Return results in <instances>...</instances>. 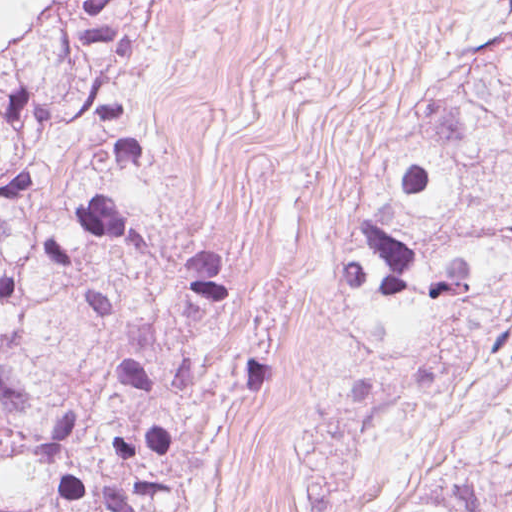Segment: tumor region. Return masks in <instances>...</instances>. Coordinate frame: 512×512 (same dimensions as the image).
Masks as SVG:
<instances>
[{
  "mask_svg": "<svg viewBox=\"0 0 512 512\" xmlns=\"http://www.w3.org/2000/svg\"><path fill=\"white\" fill-rule=\"evenodd\" d=\"M512 352V24L492 27L387 350ZM392 512H512V460L422 474Z\"/></svg>",
  "mask_w": 512,
  "mask_h": 512,
  "instance_id": "obj_1",
  "label": "tumor region"
}]
</instances>
